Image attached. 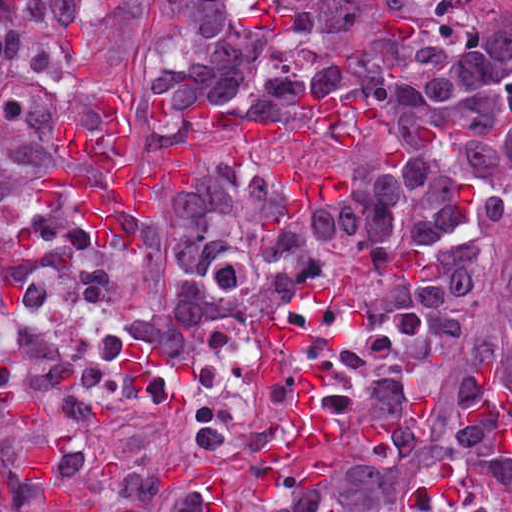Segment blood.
Here are the masks:
<instances>
[{
  "label": "blood",
  "mask_w": 512,
  "mask_h": 512,
  "mask_svg": "<svg viewBox=\"0 0 512 512\" xmlns=\"http://www.w3.org/2000/svg\"><path fill=\"white\" fill-rule=\"evenodd\" d=\"M85 152L102 181L109 201L125 216L159 215L163 191L170 181L184 182L165 164L145 175L128 154L131 125L118 98L103 100L106 131L95 133L87 121L74 114ZM34 203L50 210L43 174L31 189Z\"/></svg>",
  "instance_id": "1"
}]
</instances>
